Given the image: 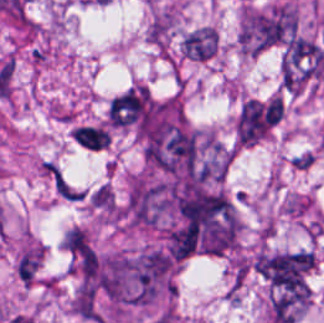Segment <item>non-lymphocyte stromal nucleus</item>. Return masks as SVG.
<instances>
[{"label":"non-lymphocyte stromal nucleus","instance_id":"1","mask_svg":"<svg viewBox=\"0 0 324 323\" xmlns=\"http://www.w3.org/2000/svg\"><path fill=\"white\" fill-rule=\"evenodd\" d=\"M39 169L58 198L78 201L83 191L52 160L43 159Z\"/></svg>","mask_w":324,"mask_h":323},{"label":"non-lymphocyte stromal nucleus","instance_id":"2","mask_svg":"<svg viewBox=\"0 0 324 323\" xmlns=\"http://www.w3.org/2000/svg\"><path fill=\"white\" fill-rule=\"evenodd\" d=\"M69 136L85 151H100L109 140L106 128L93 123L77 124Z\"/></svg>","mask_w":324,"mask_h":323},{"label":"non-lymphocyte stromal nucleus","instance_id":"3","mask_svg":"<svg viewBox=\"0 0 324 323\" xmlns=\"http://www.w3.org/2000/svg\"><path fill=\"white\" fill-rule=\"evenodd\" d=\"M181 48L185 55L203 60L214 50V33L203 27L191 31L181 40Z\"/></svg>","mask_w":324,"mask_h":323}]
</instances>
